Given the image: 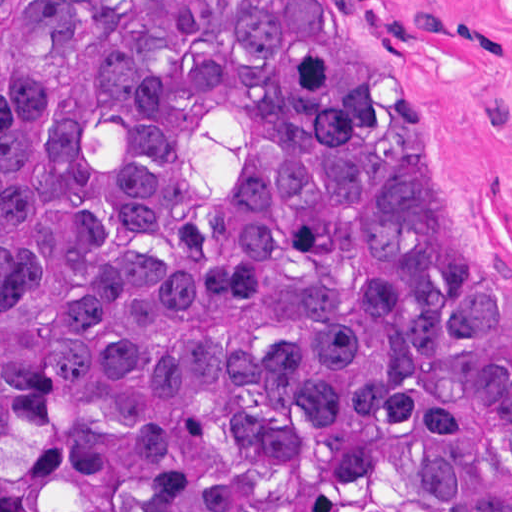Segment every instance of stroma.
<instances>
[{"mask_svg":"<svg viewBox=\"0 0 512 512\" xmlns=\"http://www.w3.org/2000/svg\"><path fill=\"white\" fill-rule=\"evenodd\" d=\"M423 164L447 248L512 349V0H334Z\"/></svg>","mask_w":512,"mask_h":512,"instance_id":"obj_1","label":"stroma"}]
</instances>
